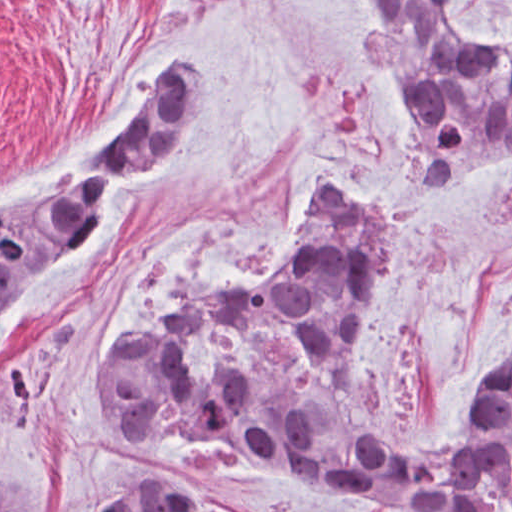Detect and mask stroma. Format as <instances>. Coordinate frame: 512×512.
Returning a JSON list of instances; mask_svg holds the SVG:
<instances>
[{"label":"stroma","mask_w":512,"mask_h":512,"mask_svg":"<svg viewBox=\"0 0 512 512\" xmlns=\"http://www.w3.org/2000/svg\"><path fill=\"white\" fill-rule=\"evenodd\" d=\"M474 47L512 41V0H451ZM214 68L201 137L168 161L33 301L0 347V464L37 512H108L151 465L206 476L256 512H411L320 476L103 418V348L155 334L193 290L284 268L310 196L355 189L401 237L361 342L356 395L389 441L464 435L512 351V161L411 197L409 113L353 0H0V204L52 189L138 126L186 59ZM214 374L263 364L310 402L332 365L290 322H224L185 346ZM489 512H512V482Z\"/></svg>","instance_id":"stroma-1"}]
</instances>
